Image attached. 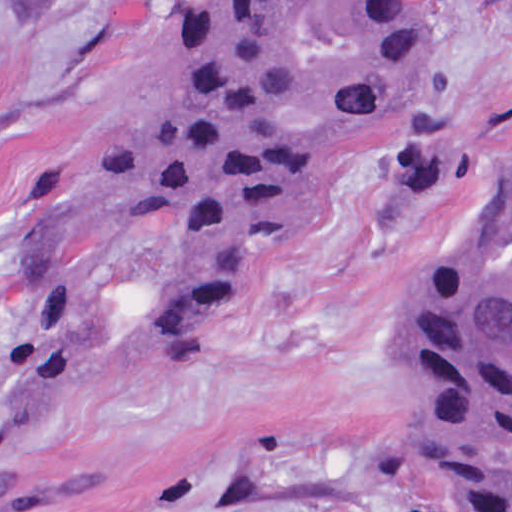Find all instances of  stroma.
Segmentation results:
<instances>
[{
    "label": "stroma",
    "mask_w": 512,
    "mask_h": 512,
    "mask_svg": "<svg viewBox=\"0 0 512 512\" xmlns=\"http://www.w3.org/2000/svg\"><path fill=\"white\" fill-rule=\"evenodd\" d=\"M192 0H0V316L25 224L79 189ZM439 126L462 176L399 209L384 153L294 235L260 247L234 297L136 365L177 227L137 216L96 245L94 351L8 444L63 493L16 512H447L409 425L394 325L411 287L463 256L512 154V0H437ZM9 371L0 365V404Z\"/></svg>",
    "instance_id": "35a3bbf8"
}]
</instances>
